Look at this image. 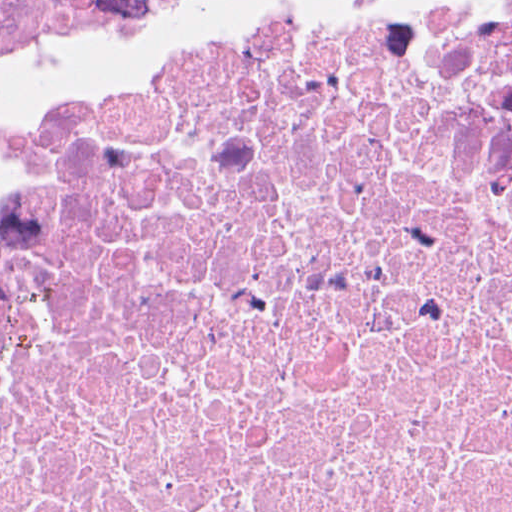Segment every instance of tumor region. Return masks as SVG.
I'll return each mask as SVG.
<instances>
[{
  "instance_id": "tumor-region-1",
  "label": "tumor region",
  "mask_w": 512,
  "mask_h": 512,
  "mask_svg": "<svg viewBox=\"0 0 512 512\" xmlns=\"http://www.w3.org/2000/svg\"><path fill=\"white\" fill-rule=\"evenodd\" d=\"M200 0H0V124Z\"/></svg>"
}]
</instances>
